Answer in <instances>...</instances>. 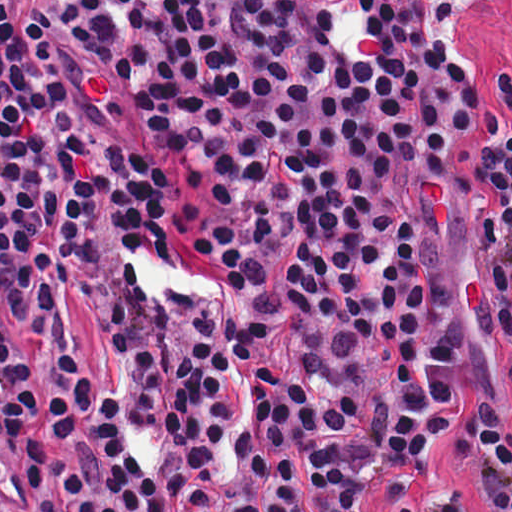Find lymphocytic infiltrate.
Segmentation results:
<instances>
[{"instance_id": "lymphocytic-infiltrate-1", "label": "lymphocytic infiltrate", "mask_w": 512, "mask_h": 512, "mask_svg": "<svg viewBox=\"0 0 512 512\" xmlns=\"http://www.w3.org/2000/svg\"><path fill=\"white\" fill-rule=\"evenodd\" d=\"M464 0H0V512H474L431 447L458 323L423 245L470 195L476 311L512 371V73ZM111 331L156 466L67 330ZM461 452L512 512V426Z\"/></svg>"}]
</instances>
